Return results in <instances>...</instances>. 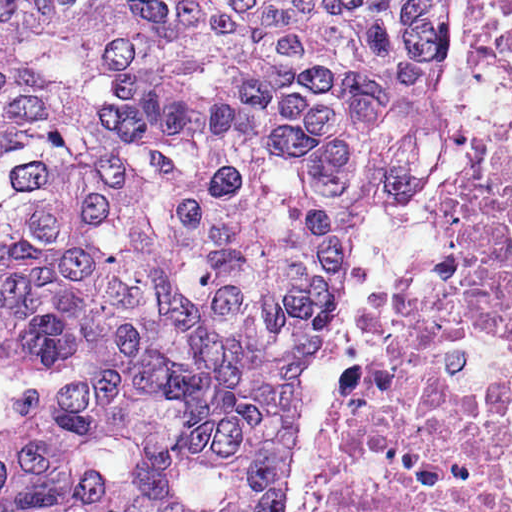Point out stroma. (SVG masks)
Returning a JSON list of instances; mask_svg holds the SVG:
<instances>
[{
	"mask_svg": "<svg viewBox=\"0 0 512 512\" xmlns=\"http://www.w3.org/2000/svg\"><path fill=\"white\" fill-rule=\"evenodd\" d=\"M492 1L457 0V65L433 103L441 141L434 163L456 157L464 165L505 125L506 64L485 58V13Z\"/></svg>",
	"mask_w": 512,
	"mask_h": 512,
	"instance_id": "35a3bbf8",
	"label": "stroma"
}]
</instances>
